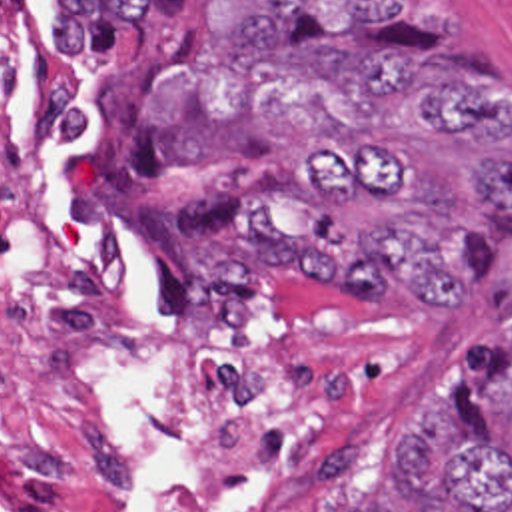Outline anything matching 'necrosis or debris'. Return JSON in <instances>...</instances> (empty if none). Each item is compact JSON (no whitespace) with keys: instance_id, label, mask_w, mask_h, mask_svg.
<instances>
[{"instance_id":"necrosis-or-debris-1","label":"necrosis or debris","mask_w":512,"mask_h":512,"mask_svg":"<svg viewBox=\"0 0 512 512\" xmlns=\"http://www.w3.org/2000/svg\"><path fill=\"white\" fill-rule=\"evenodd\" d=\"M0 512H390L384 412L328 358L198 404L90 253L52 0H0Z\"/></svg>"}]
</instances>
